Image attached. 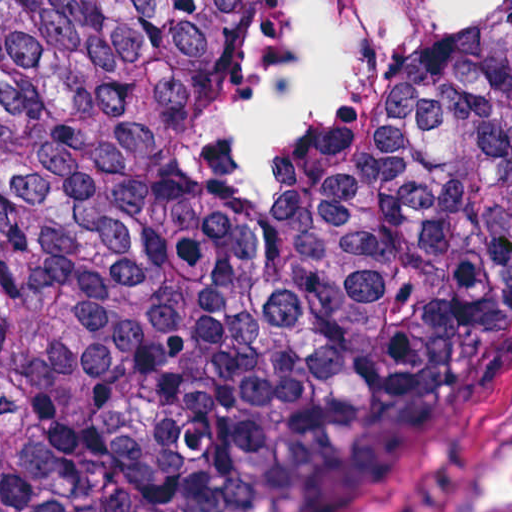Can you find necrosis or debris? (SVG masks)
I'll return each mask as SVG.
<instances>
[{
	"instance_id": "obj_1",
	"label": "necrosis or debris",
	"mask_w": 512,
	"mask_h": 512,
	"mask_svg": "<svg viewBox=\"0 0 512 512\" xmlns=\"http://www.w3.org/2000/svg\"><path fill=\"white\" fill-rule=\"evenodd\" d=\"M300 0H242L185 72L178 148L207 166H272L331 146L422 53L490 0H334L329 93L313 120L263 155H220L214 126L289 24Z\"/></svg>"
}]
</instances>
